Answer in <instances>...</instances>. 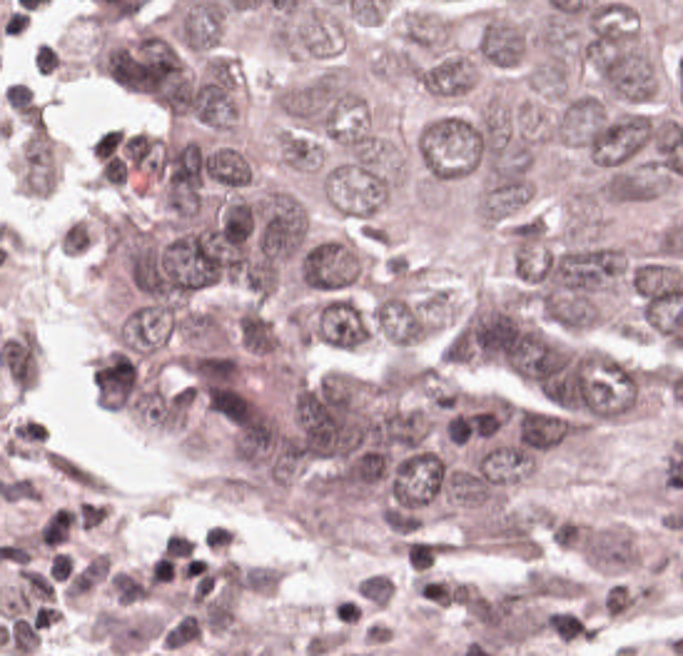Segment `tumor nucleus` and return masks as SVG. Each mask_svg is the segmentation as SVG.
<instances>
[{
  "label": "tumor nucleus",
  "instance_id": "3",
  "mask_svg": "<svg viewBox=\"0 0 683 656\" xmlns=\"http://www.w3.org/2000/svg\"><path fill=\"white\" fill-rule=\"evenodd\" d=\"M525 33L509 18L486 14L475 26L471 49L483 60L503 68H517L526 45Z\"/></svg>",
  "mask_w": 683,
  "mask_h": 656
},
{
  "label": "tumor nucleus",
  "instance_id": "1",
  "mask_svg": "<svg viewBox=\"0 0 683 656\" xmlns=\"http://www.w3.org/2000/svg\"><path fill=\"white\" fill-rule=\"evenodd\" d=\"M418 150L431 180L472 173L484 153V119L449 109L438 112L422 125Z\"/></svg>",
  "mask_w": 683,
  "mask_h": 656
},
{
  "label": "tumor nucleus",
  "instance_id": "2",
  "mask_svg": "<svg viewBox=\"0 0 683 656\" xmlns=\"http://www.w3.org/2000/svg\"><path fill=\"white\" fill-rule=\"evenodd\" d=\"M294 274L301 288L347 290L359 279V254L342 237H316L303 250Z\"/></svg>",
  "mask_w": 683,
  "mask_h": 656
}]
</instances>
